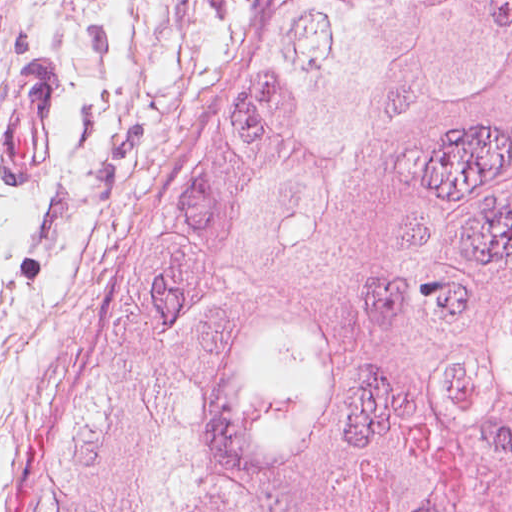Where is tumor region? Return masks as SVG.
Segmentation results:
<instances>
[{
    "label": "tumor region",
    "mask_w": 512,
    "mask_h": 512,
    "mask_svg": "<svg viewBox=\"0 0 512 512\" xmlns=\"http://www.w3.org/2000/svg\"><path fill=\"white\" fill-rule=\"evenodd\" d=\"M3 512H512V0H268Z\"/></svg>",
    "instance_id": "e687c5a6"
}]
</instances>
